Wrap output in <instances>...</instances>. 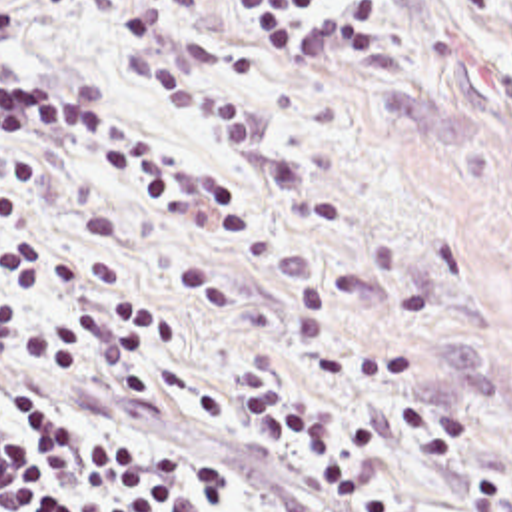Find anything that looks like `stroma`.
I'll return each mask as SVG.
<instances>
[{
  "mask_svg": "<svg viewBox=\"0 0 512 512\" xmlns=\"http://www.w3.org/2000/svg\"><path fill=\"white\" fill-rule=\"evenodd\" d=\"M134 0H0V63L42 73L80 99L134 117L206 167H220L212 215H176L96 131L56 113L0 119V197L24 219L0 241L32 239L118 267L114 283H56L40 307L74 316L142 301L176 326L148 348L146 388L52 366L0 338L6 366L72 402L194 446L228 472L238 512H405L352 0L328 3L326 51H258L236 1L182 21L194 67L258 93L262 139L238 145L134 85L118 33ZM0 289L18 301L0 267ZM288 380L328 416L372 426L366 488L332 498L302 448L248 428L234 368Z\"/></svg>",
  "mask_w": 512,
  "mask_h": 512,
  "instance_id": "obj_1",
  "label": "stroma"
}]
</instances>
